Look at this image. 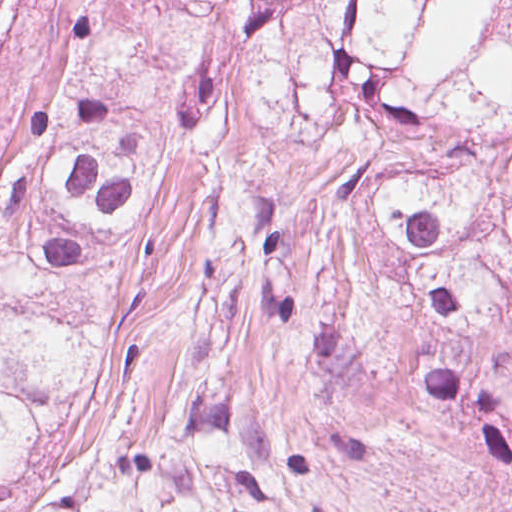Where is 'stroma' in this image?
Returning <instances> with one entry per match:
<instances>
[{"mask_svg": "<svg viewBox=\"0 0 512 512\" xmlns=\"http://www.w3.org/2000/svg\"><path fill=\"white\" fill-rule=\"evenodd\" d=\"M61 31V0H15L0 40V124ZM249 72L219 95L217 157L161 179L123 249L106 258L98 291L123 353L96 395L56 413L12 512H44L49 483L72 451L102 440L159 442L172 415L200 403L268 434L316 446L333 396L308 367V343L264 316L247 251L254 197L280 188L340 191L356 157L342 143L300 148L271 133L249 103Z\"/></svg>", "mask_w": 512, "mask_h": 512, "instance_id": "35a3bbf8", "label": "stroma"}]
</instances>
